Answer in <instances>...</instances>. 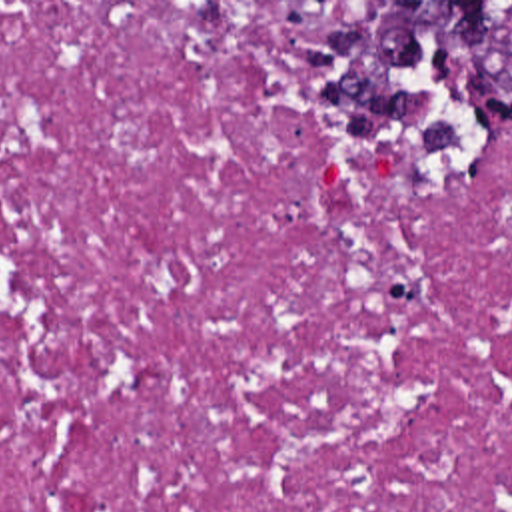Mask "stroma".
I'll return each instance as SVG.
<instances>
[{
    "label": "stroma",
    "mask_w": 512,
    "mask_h": 512,
    "mask_svg": "<svg viewBox=\"0 0 512 512\" xmlns=\"http://www.w3.org/2000/svg\"><path fill=\"white\" fill-rule=\"evenodd\" d=\"M0 2H340V10L330 14L328 18L320 20L316 26H312L308 32H304V38L308 34H312L316 28L320 26H328V24H334L338 22L340 18H344L346 14L352 12L354 4L356 2H512V0H0ZM308 72V82H310V92L314 90V82H316V76ZM314 102V98H312ZM314 112H316V118L322 120L326 126H330L332 130H336L338 134L344 136L342 132V126H340V120L336 114H318L316 110V104H314ZM346 138V136H344ZM512 140V126H494L490 130V134L484 138L482 142V148H480V154H478V162H476V170L494 154L498 152L504 144H508ZM474 170V172H476ZM430 180H458V178H430Z\"/></svg>",
    "instance_id": "obj_1"
}]
</instances>
